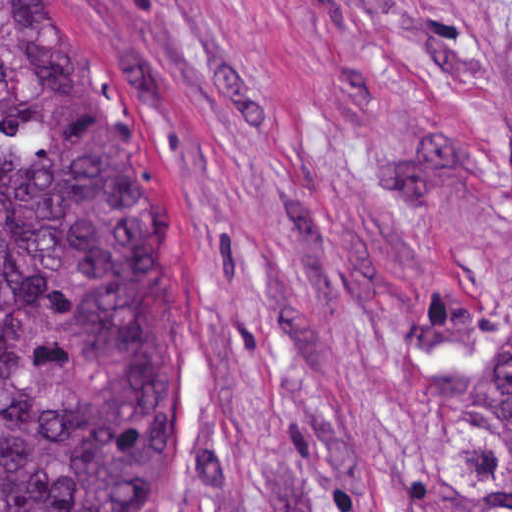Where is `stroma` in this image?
Returning a JSON list of instances; mask_svg holds the SVG:
<instances>
[{
  "mask_svg": "<svg viewBox=\"0 0 512 512\" xmlns=\"http://www.w3.org/2000/svg\"><path fill=\"white\" fill-rule=\"evenodd\" d=\"M157 158L187 351L148 512H443L512 343V0H46Z\"/></svg>",
  "mask_w": 512,
  "mask_h": 512,
  "instance_id": "1",
  "label": "stroma"
}]
</instances>
